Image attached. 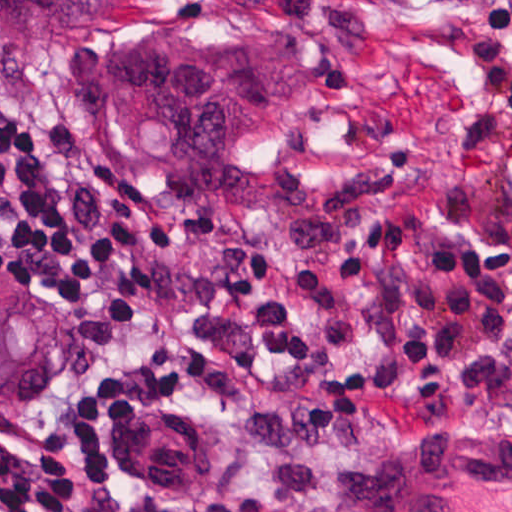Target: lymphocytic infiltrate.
Listing matches in <instances>:
<instances>
[{
  "label": "lymphocytic infiltrate",
  "instance_id": "1",
  "mask_svg": "<svg viewBox=\"0 0 512 512\" xmlns=\"http://www.w3.org/2000/svg\"><path fill=\"white\" fill-rule=\"evenodd\" d=\"M42 127L0 95V266L81 309L93 346L115 342L157 293L137 220L93 238L40 157ZM253 321L256 346L310 379L307 417L418 412L512 400V240L445 225L435 205L395 203L329 262L291 269L269 249L228 247L186 296ZM142 306L140 309H131ZM237 369L177 338L130 363L61 419L43 450L0 439V512H93L109 481L185 490L208 473L210 427L177 412L183 386L237 388Z\"/></svg>",
  "mask_w": 512,
  "mask_h": 512
}]
</instances>
